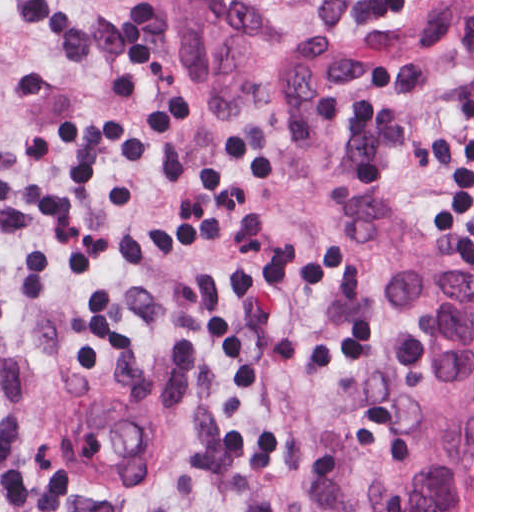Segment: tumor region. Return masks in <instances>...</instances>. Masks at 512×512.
Wrapping results in <instances>:
<instances>
[{
  "label": "tumor region",
  "mask_w": 512,
  "mask_h": 512,
  "mask_svg": "<svg viewBox=\"0 0 512 512\" xmlns=\"http://www.w3.org/2000/svg\"><path fill=\"white\" fill-rule=\"evenodd\" d=\"M108 1L213 114L282 110L269 38L240 0ZM469 35L473 0H368L344 12L335 33L340 55L359 59L413 56ZM315 209L336 265L368 298L392 348L405 449L382 479L337 434L306 512H472V261L356 189H320Z\"/></svg>",
  "instance_id": "e687c5a6"
}]
</instances>
